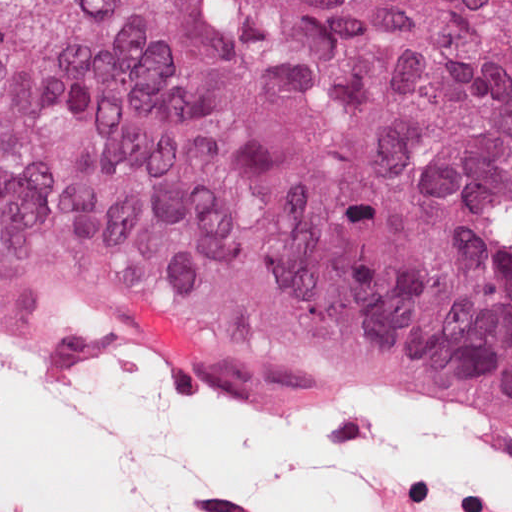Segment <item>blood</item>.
<instances>
[{"mask_svg": "<svg viewBox=\"0 0 512 512\" xmlns=\"http://www.w3.org/2000/svg\"><path fill=\"white\" fill-rule=\"evenodd\" d=\"M127 311L144 327L157 344L175 351L186 361L203 362L210 357V353L192 335L168 323Z\"/></svg>", "mask_w": 512, "mask_h": 512, "instance_id": "1a1defca", "label": "blood"}]
</instances>
